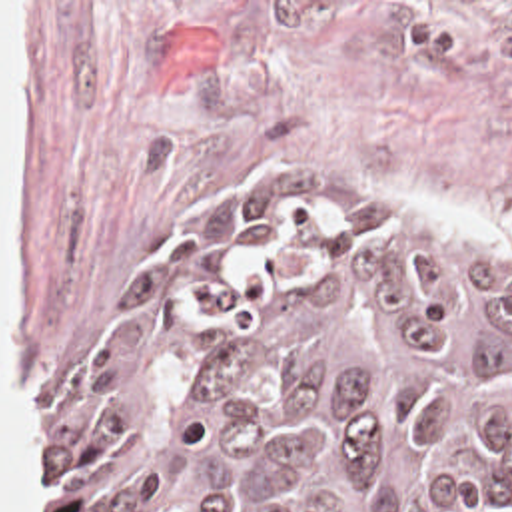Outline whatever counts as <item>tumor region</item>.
<instances>
[{"label": "tumor region", "mask_w": 512, "mask_h": 512, "mask_svg": "<svg viewBox=\"0 0 512 512\" xmlns=\"http://www.w3.org/2000/svg\"><path fill=\"white\" fill-rule=\"evenodd\" d=\"M53 512H502L512 266L229 176L53 403Z\"/></svg>", "instance_id": "e687c5a6"}]
</instances>
